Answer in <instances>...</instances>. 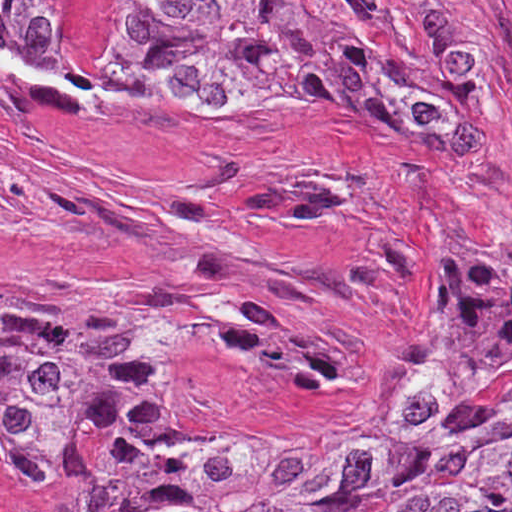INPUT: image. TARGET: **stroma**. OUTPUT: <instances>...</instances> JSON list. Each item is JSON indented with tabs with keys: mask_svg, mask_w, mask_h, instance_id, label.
Instances as JSON below:
<instances>
[{
	"mask_svg": "<svg viewBox=\"0 0 512 512\" xmlns=\"http://www.w3.org/2000/svg\"><path fill=\"white\" fill-rule=\"evenodd\" d=\"M0 33L52 76L1 13ZM478 48L496 88L479 139L400 111L256 114L0 73V276L229 293L239 322L175 317L156 390L363 439L463 241L468 181L475 247L512 272V0H478ZM359 447L318 455L347 477ZM80 501V467L36 486L0 455V512Z\"/></svg>",
	"mask_w": 512,
	"mask_h": 512,
	"instance_id": "1",
	"label": "stroma"
}]
</instances>
